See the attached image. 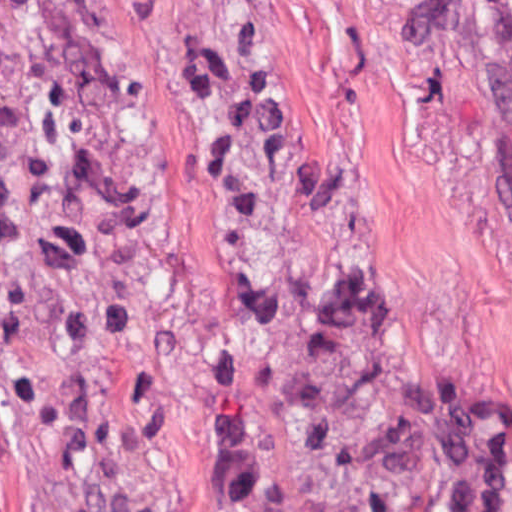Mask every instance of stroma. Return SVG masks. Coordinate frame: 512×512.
<instances>
[{"label":"stroma","mask_w":512,"mask_h":512,"mask_svg":"<svg viewBox=\"0 0 512 512\" xmlns=\"http://www.w3.org/2000/svg\"><path fill=\"white\" fill-rule=\"evenodd\" d=\"M225 1L373 268L461 512H512V9ZM72 2L188 435L224 512H278L241 372L227 131L186 0ZM0 512H51L1 359Z\"/></svg>","instance_id":"obj_1"}]
</instances>
